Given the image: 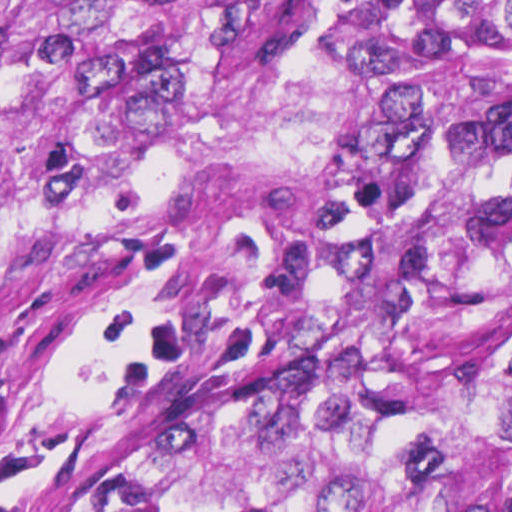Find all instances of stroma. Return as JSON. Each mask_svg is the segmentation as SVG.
<instances>
[{
	"instance_id": "35a3bbf8",
	"label": "stroma",
	"mask_w": 512,
	"mask_h": 512,
	"mask_svg": "<svg viewBox=\"0 0 512 512\" xmlns=\"http://www.w3.org/2000/svg\"><path fill=\"white\" fill-rule=\"evenodd\" d=\"M247 305L213 274L102 239L1 268L0 512H48L92 450L226 349Z\"/></svg>"
}]
</instances>
